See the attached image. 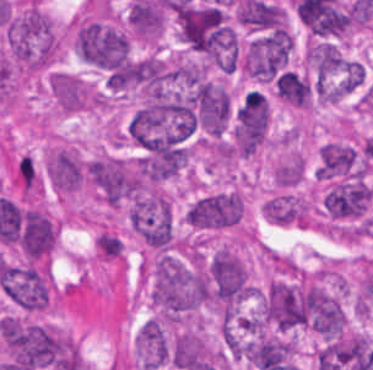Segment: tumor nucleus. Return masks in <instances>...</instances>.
<instances>
[{
  "mask_svg": "<svg viewBox=\"0 0 373 370\" xmlns=\"http://www.w3.org/2000/svg\"><path fill=\"white\" fill-rule=\"evenodd\" d=\"M3 43L12 65L24 71L45 69L57 54L56 33L33 0H26L9 14Z\"/></svg>",
  "mask_w": 373,
  "mask_h": 370,
  "instance_id": "obj_1",
  "label": "tumor nucleus"
},
{
  "mask_svg": "<svg viewBox=\"0 0 373 370\" xmlns=\"http://www.w3.org/2000/svg\"><path fill=\"white\" fill-rule=\"evenodd\" d=\"M201 294L215 306L239 305L251 294L244 263L227 247H220L206 261Z\"/></svg>",
  "mask_w": 373,
  "mask_h": 370,
  "instance_id": "obj_2",
  "label": "tumor nucleus"
},
{
  "mask_svg": "<svg viewBox=\"0 0 373 370\" xmlns=\"http://www.w3.org/2000/svg\"><path fill=\"white\" fill-rule=\"evenodd\" d=\"M87 180L100 199L117 206L141 194V164L137 160L97 155L88 160Z\"/></svg>",
  "mask_w": 373,
  "mask_h": 370,
  "instance_id": "obj_3",
  "label": "tumor nucleus"
},
{
  "mask_svg": "<svg viewBox=\"0 0 373 370\" xmlns=\"http://www.w3.org/2000/svg\"><path fill=\"white\" fill-rule=\"evenodd\" d=\"M125 218L129 228L149 248L171 247L173 227L169 198L155 188H148L129 202Z\"/></svg>",
  "mask_w": 373,
  "mask_h": 370,
  "instance_id": "obj_4",
  "label": "tumor nucleus"
},
{
  "mask_svg": "<svg viewBox=\"0 0 373 370\" xmlns=\"http://www.w3.org/2000/svg\"><path fill=\"white\" fill-rule=\"evenodd\" d=\"M372 195L367 173L334 178L321 194V212L324 219L335 222L364 220Z\"/></svg>",
  "mask_w": 373,
  "mask_h": 370,
  "instance_id": "obj_5",
  "label": "tumor nucleus"
},
{
  "mask_svg": "<svg viewBox=\"0 0 373 370\" xmlns=\"http://www.w3.org/2000/svg\"><path fill=\"white\" fill-rule=\"evenodd\" d=\"M183 40L197 52L215 53L234 42L232 30L216 6H188L178 15Z\"/></svg>",
  "mask_w": 373,
  "mask_h": 370,
  "instance_id": "obj_6",
  "label": "tumor nucleus"
},
{
  "mask_svg": "<svg viewBox=\"0 0 373 370\" xmlns=\"http://www.w3.org/2000/svg\"><path fill=\"white\" fill-rule=\"evenodd\" d=\"M72 46L80 60L108 69L120 64L126 53L124 37L110 26L94 20L75 24Z\"/></svg>",
  "mask_w": 373,
  "mask_h": 370,
  "instance_id": "obj_7",
  "label": "tumor nucleus"
},
{
  "mask_svg": "<svg viewBox=\"0 0 373 370\" xmlns=\"http://www.w3.org/2000/svg\"><path fill=\"white\" fill-rule=\"evenodd\" d=\"M242 215L240 192L227 189L195 198L186 208L184 221L197 231H216L238 225Z\"/></svg>",
  "mask_w": 373,
  "mask_h": 370,
  "instance_id": "obj_8",
  "label": "tumor nucleus"
},
{
  "mask_svg": "<svg viewBox=\"0 0 373 370\" xmlns=\"http://www.w3.org/2000/svg\"><path fill=\"white\" fill-rule=\"evenodd\" d=\"M290 49L288 33L280 27L250 38L242 70L254 79L270 80L287 60Z\"/></svg>",
  "mask_w": 373,
  "mask_h": 370,
  "instance_id": "obj_9",
  "label": "tumor nucleus"
},
{
  "mask_svg": "<svg viewBox=\"0 0 373 370\" xmlns=\"http://www.w3.org/2000/svg\"><path fill=\"white\" fill-rule=\"evenodd\" d=\"M368 172L365 161L354 145L340 140L325 141L318 150L314 175L323 182Z\"/></svg>",
  "mask_w": 373,
  "mask_h": 370,
  "instance_id": "obj_10",
  "label": "tumor nucleus"
},
{
  "mask_svg": "<svg viewBox=\"0 0 373 370\" xmlns=\"http://www.w3.org/2000/svg\"><path fill=\"white\" fill-rule=\"evenodd\" d=\"M45 175L54 192L71 193L84 183L85 160L73 146H60L46 155Z\"/></svg>",
  "mask_w": 373,
  "mask_h": 370,
  "instance_id": "obj_11",
  "label": "tumor nucleus"
},
{
  "mask_svg": "<svg viewBox=\"0 0 373 370\" xmlns=\"http://www.w3.org/2000/svg\"><path fill=\"white\" fill-rule=\"evenodd\" d=\"M46 86L51 99L64 112L97 108L99 104L95 91L67 71L54 70L46 76Z\"/></svg>",
  "mask_w": 373,
  "mask_h": 370,
  "instance_id": "obj_12",
  "label": "tumor nucleus"
},
{
  "mask_svg": "<svg viewBox=\"0 0 373 370\" xmlns=\"http://www.w3.org/2000/svg\"><path fill=\"white\" fill-rule=\"evenodd\" d=\"M56 229L41 209L26 207L22 209L18 243L28 259L46 257L54 247Z\"/></svg>",
  "mask_w": 373,
  "mask_h": 370,
  "instance_id": "obj_13",
  "label": "tumor nucleus"
},
{
  "mask_svg": "<svg viewBox=\"0 0 373 370\" xmlns=\"http://www.w3.org/2000/svg\"><path fill=\"white\" fill-rule=\"evenodd\" d=\"M265 219L272 225L305 227L313 221L309 204L292 193H279L265 200Z\"/></svg>",
  "mask_w": 373,
  "mask_h": 370,
  "instance_id": "obj_14",
  "label": "tumor nucleus"
},
{
  "mask_svg": "<svg viewBox=\"0 0 373 370\" xmlns=\"http://www.w3.org/2000/svg\"><path fill=\"white\" fill-rule=\"evenodd\" d=\"M302 171L303 159L292 151L274 167V182L277 185H294L300 181Z\"/></svg>",
  "mask_w": 373,
  "mask_h": 370,
  "instance_id": "obj_15",
  "label": "tumor nucleus"
}]
</instances>
